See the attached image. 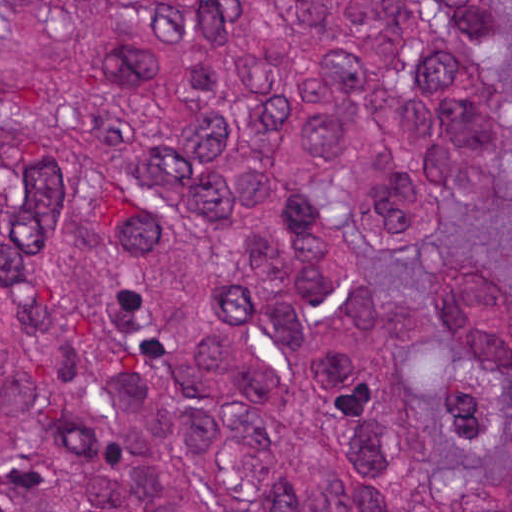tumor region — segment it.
<instances>
[{"instance_id":"tumor-region-1","label":"tumor region","mask_w":512,"mask_h":512,"mask_svg":"<svg viewBox=\"0 0 512 512\" xmlns=\"http://www.w3.org/2000/svg\"><path fill=\"white\" fill-rule=\"evenodd\" d=\"M512 1H1V512H512Z\"/></svg>"}]
</instances>
